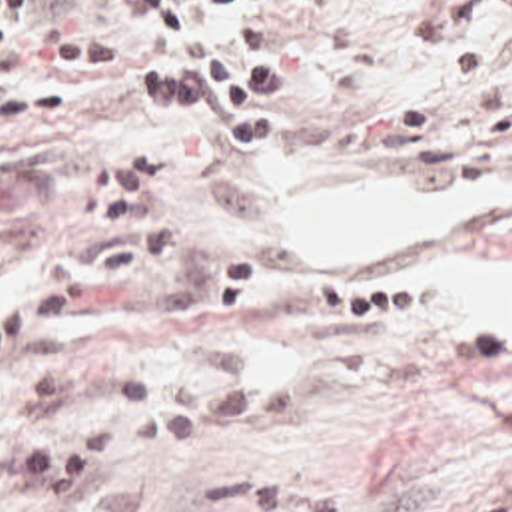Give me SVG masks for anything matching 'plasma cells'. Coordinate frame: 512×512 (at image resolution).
Listing matches in <instances>:
<instances>
[{"label": "plasma cells", "mask_w": 512, "mask_h": 512, "mask_svg": "<svg viewBox=\"0 0 512 512\" xmlns=\"http://www.w3.org/2000/svg\"><path fill=\"white\" fill-rule=\"evenodd\" d=\"M197 433V409L179 405L143 429L119 417H87L25 443L11 471L31 512H145L119 481L147 455L163 453Z\"/></svg>", "instance_id": "9512152a"}]
</instances>
